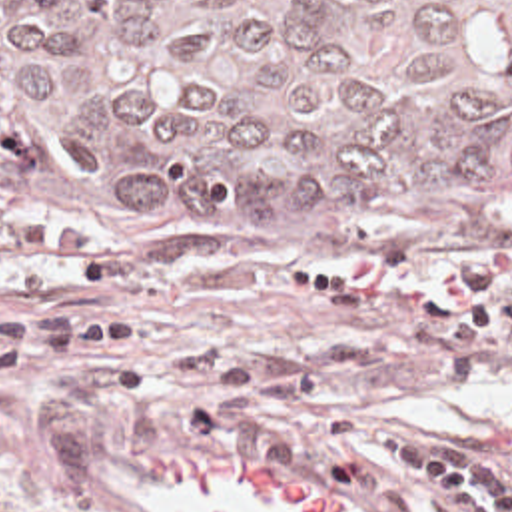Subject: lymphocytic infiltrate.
Wrapping results in <instances>:
<instances>
[{"mask_svg": "<svg viewBox=\"0 0 512 512\" xmlns=\"http://www.w3.org/2000/svg\"><path fill=\"white\" fill-rule=\"evenodd\" d=\"M454 294H410L340 282L324 272L289 268L275 286L372 318L424 322L448 370H486L512 348V290H494L488 270L468 264ZM121 266L83 234L51 218H17L0 240V380L29 376L55 362L125 360L143 352V326L127 316L91 310H11L5 294L67 296L111 290Z\"/></svg>", "mask_w": 512, "mask_h": 512, "instance_id": "f902f5d3", "label": "lymphocytic infiltrate"}]
</instances>
